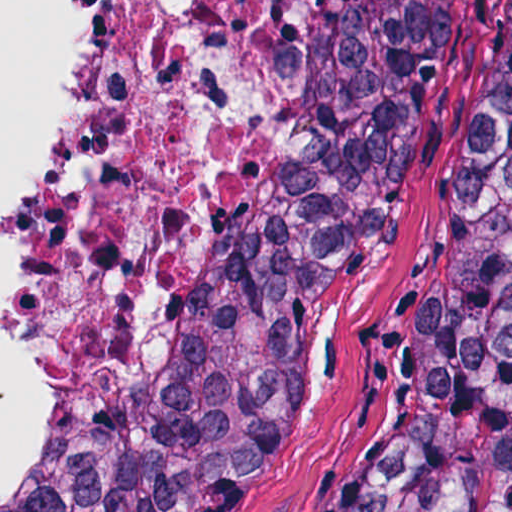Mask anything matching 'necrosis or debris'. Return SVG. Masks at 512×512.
I'll use <instances>...</instances> for the list:
<instances>
[{"label": "necrosis or debris", "mask_w": 512, "mask_h": 512, "mask_svg": "<svg viewBox=\"0 0 512 512\" xmlns=\"http://www.w3.org/2000/svg\"><path fill=\"white\" fill-rule=\"evenodd\" d=\"M311 4L97 0L23 293L34 435L0 496L106 436L187 344Z\"/></svg>", "instance_id": "4bbe7bcc"}]
</instances>
